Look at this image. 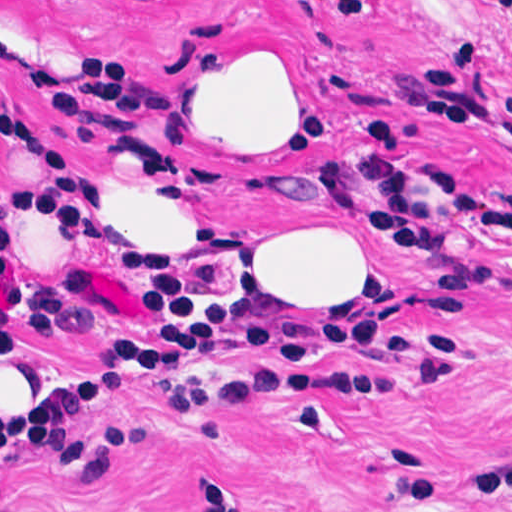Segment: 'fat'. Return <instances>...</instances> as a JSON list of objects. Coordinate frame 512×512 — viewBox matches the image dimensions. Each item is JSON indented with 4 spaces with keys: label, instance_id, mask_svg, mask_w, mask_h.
I'll return each mask as SVG.
<instances>
[{
    "label": "fat",
    "instance_id": "1",
    "mask_svg": "<svg viewBox=\"0 0 512 512\" xmlns=\"http://www.w3.org/2000/svg\"><path fill=\"white\" fill-rule=\"evenodd\" d=\"M182 137L243 183L289 189L316 173L326 149L316 70L285 46L227 51L182 106ZM128 203L158 274H199L224 258V216L208 179L175 166ZM261 251H273L279 282L301 303L368 289L391 270L346 221H314Z\"/></svg>",
    "mask_w": 512,
    "mask_h": 512
}]
</instances>
